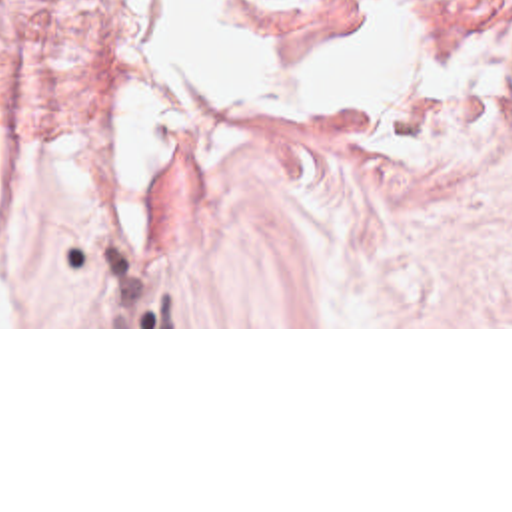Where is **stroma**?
Here are the masks:
<instances>
[{"label": "stroma", "instance_id": "1", "mask_svg": "<svg viewBox=\"0 0 512 512\" xmlns=\"http://www.w3.org/2000/svg\"><path fill=\"white\" fill-rule=\"evenodd\" d=\"M225 2L269 63L331 59L351 8L423 46L512 44V0ZM159 4L0 0V151L145 85L187 129L163 211L0 329H512V97L481 125L273 115L165 69Z\"/></svg>", "mask_w": 512, "mask_h": 512}]
</instances>
